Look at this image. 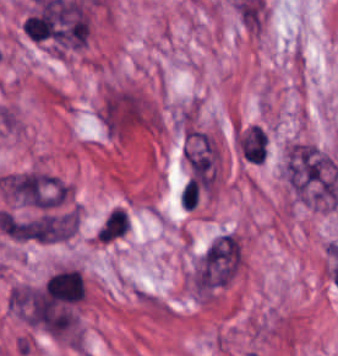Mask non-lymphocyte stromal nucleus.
<instances>
[{
    "instance_id": "1",
    "label": "non-lymphocyte stromal nucleus",
    "mask_w": 338,
    "mask_h": 356,
    "mask_svg": "<svg viewBox=\"0 0 338 356\" xmlns=\"http://www.w3.org/2000/svg\"><path fill=\"white\" fill-rule=\"evenodd\" d=\"M284 174L293 194L307 206H334L338 200V167L332 156L315 144L288 146Z\"/></svg>"
},
{
    "instance_id": "2",
    "label": "non-lymphocyte stromal nucleus",
    "mask_w": 338,
    "mask_h": 356,
    "mask_svg": "<svg viewBox=\"0 0 338 356\" xmlns=\"http://www.w3.org/2000/svg\"><path fill=\"white\" fill-rule=\"evenodd\" d=\"M0 188L18 203L49 209L65 197L63 184L46 173L21 172L2 177Z\"/></svg>"
},
{
    "instance_id": "3",
    "label": "non-lymphocyte stromal nucleus",
    "mask_w": 338,
    "mask_h": 356,
    "mask_svg": "<svg viewBox=\"0 0 338 356\" xmlns=\"http://www.w3.org/2000/svg\"><path fill=\"white\" fill-rule=\"evenodd\" d=\"M241 264L238 238L218 237L204 252L198 264V285L219 286L230 281Z\"/></svg>"
},
{
    "instance_id": "4",
    "label": "non-lymphocyte stromal nucleus",
    "mask_w": 338,
    "mask_h": 356,
    "mask_svg": "<svg viewBox=\"0 0 338 356\" xmlns=\"http://www.w3.org/2000/svg\"><path fill=\"white\" fill-rule=\"evenodd\" d=\"M11 297L27 324L54 331L59 325L54 300L46 291L30 287L15 286Z\"/></svg>"
},
{
    "instance_id": "5",
    "label": "non-lymphocyte stromal nucleus",
    "mask_w": 338,
    "mask_h": 356,
    "mask_svg": "<svg viewBox=\"0 0 338 356\" xmlns=\"http://www.w3.org/2000/svg\"><path fill=\"white\" fill-rule=\"evenodd\" d=\"M183 155L194 168H202L218 156L208 135L189 130L185 137Z\"/></svg>"
}]
</instances>
